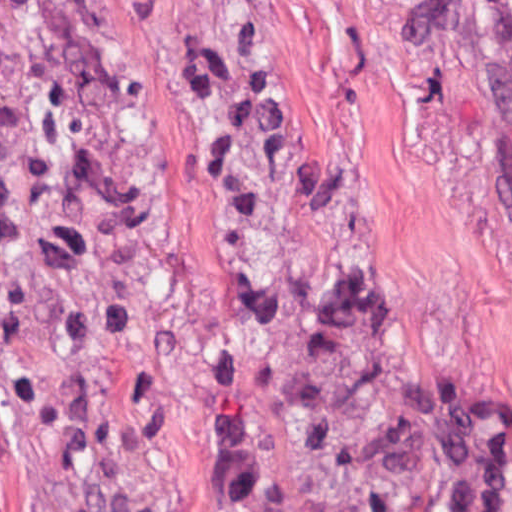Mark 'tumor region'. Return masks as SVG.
Here are the masks:
<instances>
[{
  "instance_id": "1",
  "label": "tumor region",
  "mask_w": 512,
  "mask_h": 512,
  "mask_svg": "<svg viewBox=\"0 0 512 512\" xmlns=\"http://www.w3.org/2000/svg\"><path fill=\"white\" fill-rule=\"evenodd\" d=\"M512 9V0H500ZM237 195V336L278 512H461L373 268L225 0H186ZM0 359L51 512H224L143 294L72 0H0Z\"/></svg>"
}]
</instances>
